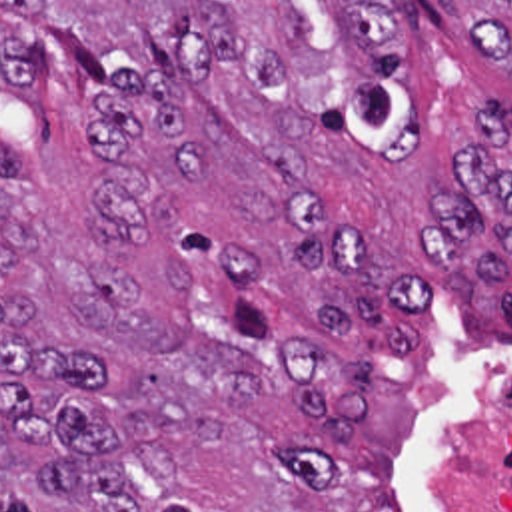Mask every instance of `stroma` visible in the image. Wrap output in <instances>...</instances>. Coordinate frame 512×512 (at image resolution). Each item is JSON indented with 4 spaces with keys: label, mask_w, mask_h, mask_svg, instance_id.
Wrapping results in <instances>:
<instances>
[{
    "label": "stroma",
    "mask_w": 512,
    "mask_h": 512,
    "mask_svg": "<svg viewBox=\"0 0 512 512\" xmlns=\"http://www.w3.org/2000/svg\"><path fill=\"white\" fill-rule=\"evenodd\" d=\"M82 30L102 36L100 60L112 72L134 68L162 76L182 128L210 154L196 188L164 192L172 222L208 236L256 264L252 306L298 341L322 353L362 357L376 383L408 393V419L392 455L398 499L406 512H457L453 465L463 409L497 377L512 371V252L509 268L471 284L463 300H445L441 268L422 258V234L434 222V198L465 190L451 158L471 120L489 102L512 112V80L493 58L459 40L453 8L408 0L420 14L410 42V84L424 108V148L402 168H384L318 120L300 140L312 184L284 176L264 146V92L224 62L190 82L170 48V0H50ZM0 22L20 38L26 82L62 50L54 36L0 2ZM20 86H0V106ZM493 160L512 170V142ZM310 212L326 224L376 236L374 268L386 278H432V304L406 312L420 331L414 351H364L334 333L326 304H352L358 286L346 268L300 270L292 260L312 244ZM98 222V212H96Z\"/></svg>",
    "instance_id": "stroma-1"
}]
</instances>
